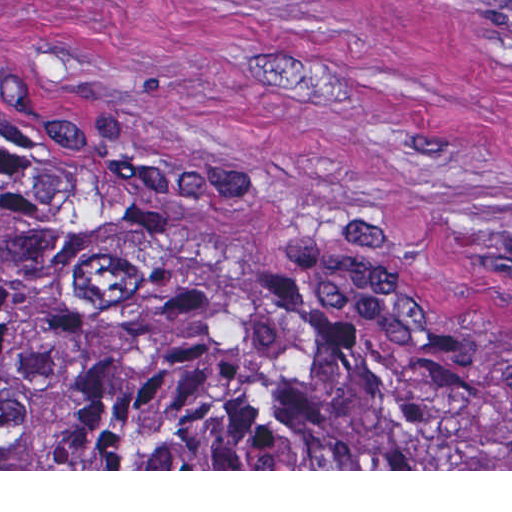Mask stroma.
<instances>
[{"label": "stroma", "mask_w": 512, "mask_h": 512, "mask_svg": "<svg viewBox=\"0 0 512 512\" xmlns=\"http://www.w3.org/2000/svg\"><path fill=\"white\" fill-rule=\"evenodd\" d=\"M0 121L174 185L237 261L448 334L512 392V0H0Z\"/></svg>", "instance_id": "obj_1"}]
</instances>
